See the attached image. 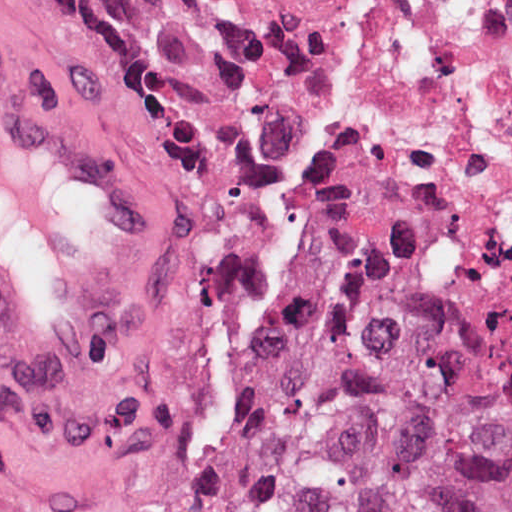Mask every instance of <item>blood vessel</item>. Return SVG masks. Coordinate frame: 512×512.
<instances>
[{
    "mask_svg": "<svg viewBox=\"0 0 512 512\" xmlns=\"http://www.w3.org/2000/svg\"><path fill=\"white\" fill-rule=\"evenodd\" d=\"M148 177L0 60V380L74 376L105 355Z\"/></svg>",
    "mask_w": 512,
    "mask_h": 512,
    "instance_id": "blood-vessel-1",
    "label": "blood vessel"
}]
</instances>
